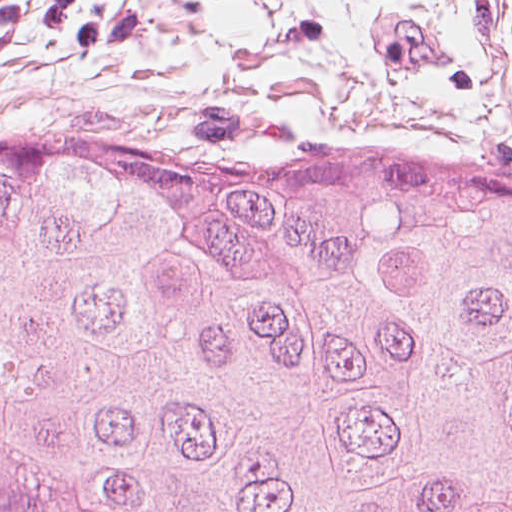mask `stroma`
<instances>
[{
    "label": "stroma",
    "instance_id": "35a3bbf8",
    "mask_svg": "<svg viewBox=\"0 0 512 512\" xmlns=\"http://www.w3.org/2000/svg\"><path fill=\"white\" fill-rule=\"evenodd\" d=\"M13 119L162 156L401 141L512 170V137L0 29V120Z\"/></svg>",
    "mask_w": 512,
    "mask_h": 512
}]
</instances>
